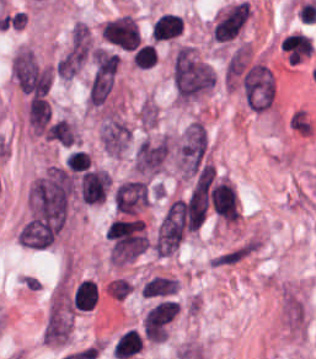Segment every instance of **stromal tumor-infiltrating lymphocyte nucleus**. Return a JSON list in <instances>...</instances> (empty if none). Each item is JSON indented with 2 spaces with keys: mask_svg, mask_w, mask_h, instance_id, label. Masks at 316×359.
I'll return each mask as SVG.
<instances>
[{
  "mask_svg": "<svg viewBox=\"0 0 316 359\" xmlns=\"http://www.w3.org/2000/svg\"><path fill=\"white\" fill-rule=\"evenodd\" d=\"M213 210L227 221L239 217L237 191L223 178L211 187L209 195Z\"/></svg>",
  "mask_w": 316,
  "mask_h": 359,
  "instance_id": "1",
  "label": "stromal tumor-infiltrating lymphocyte nucleus"
},
{
  "mask_svg": "<svg viewBox=\"0 0 316 359\" xmlns=\"http://www.w3.org/2000/svg\"><path fill=\"white\" fill-rule=\"evenodd\" d=\"M109 186V176L104 169L94 168L83 172L79 178L80 200L88 204L102 201Z\"/></svg>",
  "mask_w": 316,
  "mask_h": 359,
  "instance_id": "2",
  "label": "stromal tumor-infiltrating lymphocyte nucleus"
},
{
  "mask_svg": "<svg viewBox=\"0 0 316 359\" xmlns=\"http://www.w3.org/2000/svg\"><path fill=\"white\" fill-rule=\"evenodd\" d=\"M143 348L142 337L136 329H129L119 336L111 351L115 359H127L139 354Z\"/></svg>",
  "mask_w": 316,
  "mask_h": 359,
  "instance_id": "3",
  "label": "stromal tumor-infiltrating lymphocyte nucleus"
},
{
  "mask_svg": "<svg viewBox=\"0 0 316 359\" xmlns=\"http://www.w3.org/2000/svg\"><path fill=\"white\" fill-rule=\"evenodd\" d=\"M184 19L176 14L164 13L158 17L152 27L153 38L158 42L181 35Z\"/></svg>",
  "mask_w": 316,
  "mask_h": 359,
  "instance_id": "4",
  "label": "stromal tumor-infiltrating lymphocyte nucleus"
},
{
  "mask_svg": "<svg viewBox=\"0 0 316 359\" xmlns=\"http://www.w3.org/2000/svg\"><path fill=\"white\" fill-rule=\"evenodd\" d=\"M97 302V286L90 280L79 282L72 299L73 307L81 310L90 309Z\"/></svg>",
  "mask_w": 316,
  "mask_h": 359,
  "instance_id": "5",
  "label": "stromal tumor-infiltrating lymphocyte nucleus"
},
{
  "mask_svg": "<svg viewBox=\"0 0 316 359\" xmlns=\"http://www.w3.org/2000/svg\"><path fill=\"white\" fill-rule=\"evenodd\" d=\"M131 60L138 68H152L157 60V51L150 43H143L137 47Z\"/></svg>",
  "mask_w": 316,
  "mask_h": 359,
  "instance_id": "6",
  "label": "stromal tumor-infiltrating lymphocyte nucleus"
}]
</instances>
